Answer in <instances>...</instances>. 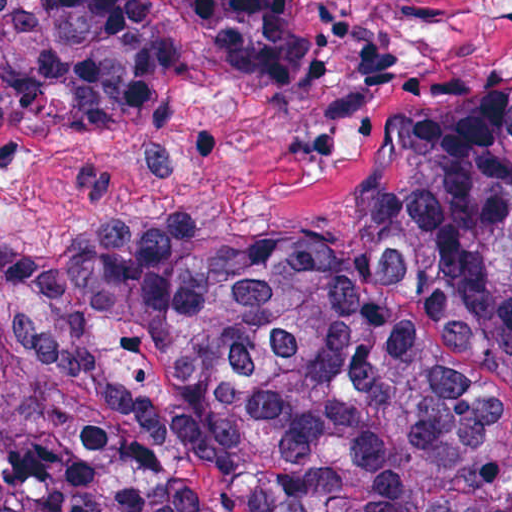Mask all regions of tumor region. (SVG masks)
Segmentation results:
<instances>
[{"label": "tumor region", "mask_w": 512, "mask_h": 512, "mask_svg": "<svg viewBox=\"0 0 512 512\" xmlns=\"http://www.w3.org/2000/svg\"><path fill=\"white\" fill-rule=\"evenodd\" d=\"M230 70L293 0H170ZM146 0H0V126L130 118ZM0 512H512V77L393 113L329 230L0 220Z\"/></svg>", "instance_id": "obj_1"}]
</instances>
